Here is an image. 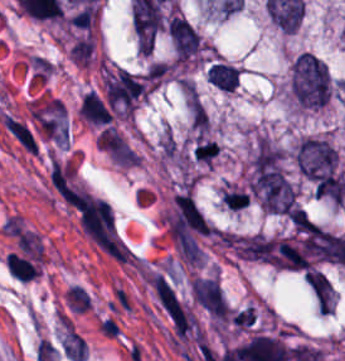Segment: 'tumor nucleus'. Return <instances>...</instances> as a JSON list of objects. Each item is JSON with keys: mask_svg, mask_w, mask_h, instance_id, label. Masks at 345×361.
<instances>
[{"mask_svg": "<svg viewBox=\"0 0 345 361\" xmlns=\"http://www.w3.org/2000/svg\"><path fill=\"white\" fill-rule=\"evenodd\" d=\"M296 164L300 174L318 191H323L339 174L337 153L323 136H304L296 147Z\"/></svg>", "mask_w": 345, "mask_h": 361, "instance_id": "2f306a5c", "label": "tumor nucleus"}, {"mask_svg": "<svg viewBox=\"0 0 345 361\" xmlns=\"http://www.w3.org/2000/svg\"><path fill=\"white\" fill-rule=\"evenodd\" d=\"M293 97L306 107H323L331 93L328 65L311 52L299 54L293 65L291 79Z\"/></svg>", "mask_w": 345, "mask_h": 361, "instance_id": "8643909e", "label": "tumor nucleus"}, {"mask_svg": "<svg viewBox=\"0 0 345 361\" xmlns=\"http://www.w3.org/2000/svg\"><path fill=\"white\" fill-rule=\"evenodd\" d=\"M194 299L216 320H225L230 307L219 279L212 275H199L192 283Z\"/></svg>", "mask_w": 345, "mask_h": 361, "instance_id": "5ab6c2c4", "label": "tumor nucleus"}, {"mask_svg": "<svg viewBox=\"0 0 345 361\" xmlns=\"http://www.w3.org/2000/svg\"><path fill=\"white\" fill-rule=\"evenodd\" d=\"M170 34L177 60H188L204 53L205 43L196 28L171 27Z\"/></svg>", "mask_w": 345, "mask_h": 361, "instance_id": "2cbd58db", "label": "tumor nucleus"}, {"mask_svg": "<svg viewBox=\"0 0 345 361\" xmlns=\"http://www.w3.org/2000/svg\"><path fill=\"white\" fill-rule=\"evenodd\" d=\"M306 281L324 312H334L335 288L327 274L317 269L307 270Z\"/></svg>", "mask_w": 345, "mask_h": 361, "instance_id": "3d1891a8", "label": "tumor nucleus"}, {"mask_svg": "<svg viewBox=\"0 0 345 361\" xmlns=\"http://www.w3.org/2000/svg\"><path fill=\"white\" fill-rule=\"evenodd\" d=\"M206 76L209 82L223 91H233L240 82V72L233 63L214 59L210 62Z\"/></svg>", "mask_w": 345, "mask_h": 361, "instance_id": "2083b535", "label": "tumor nucleus"}]
</instances>
